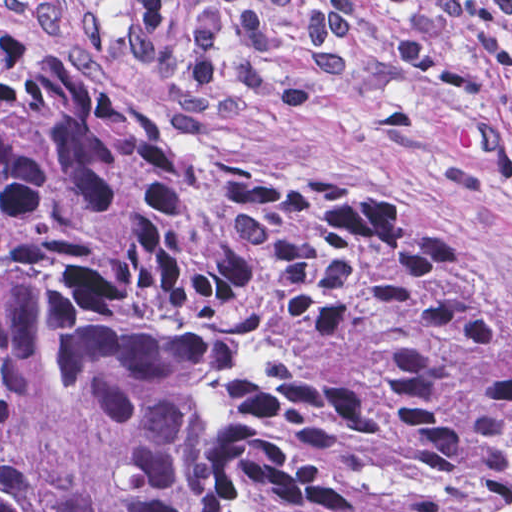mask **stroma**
<instances>
[{"label": "stroma", "mask_w": 512, "mask_h": 512, "mask_svg": "<svg viewBox=\"0 0 512 512\" xmlns=\"http://www.w3.org/2000/svg\"><path fill=\"white\" fill-rule=\"evenodd\" d=\"M31 3L0 0V10L39 43L107 76L171 133L161 80L135 69L124 47L91 51L76 26L33 27ZM396 18L369 10L357 62L339 74L313 64L307 23L279 20V62L303 79L305 101H245L186 141L400 198L476 267L512 326V61L488 71L451 31L404 71L393 59Z\"/></svg>", "instance_id": "stroma-1"}]
</instances>
